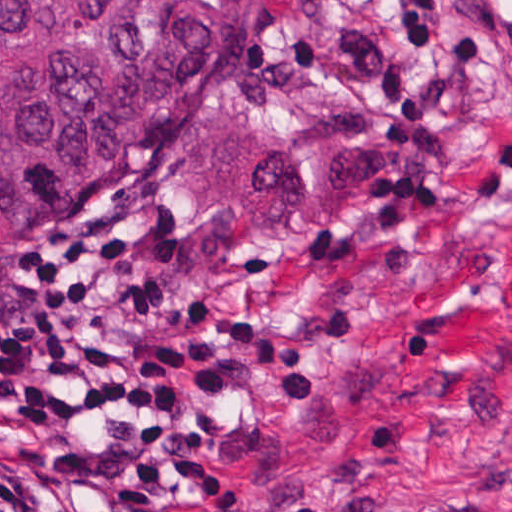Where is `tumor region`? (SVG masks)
Listing matches in <instances>:
<instances>
[{
  "mask_svg": "<svg viewBox=\"0 0 512 512\" xmlns=\"http://www.w3.org/2000/svg\"><path fill=\"white\" fill-rule=\"evenodd\" d=\"M250 0H0V266L184 117Z\"/></svg>",
  "mask_w": 512,
  "mask_h": 512,
  "instance_id": "1",
  "label": "tumor region"
}]
</instances>
